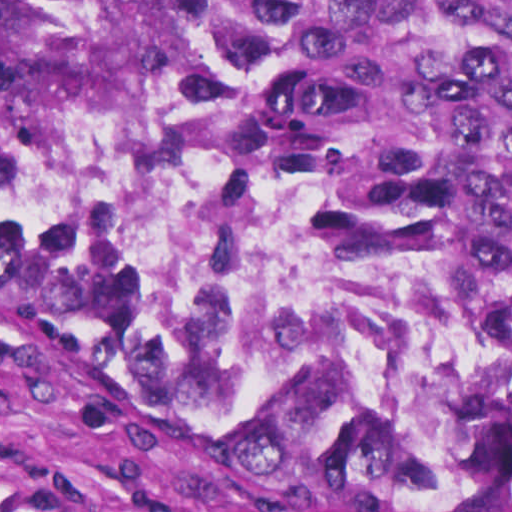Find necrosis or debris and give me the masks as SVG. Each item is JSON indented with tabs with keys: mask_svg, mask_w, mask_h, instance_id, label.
Instances as JSON below:
<instances>
[{
	"mask_svg": "<svg viewBox=\"0 0 512 512\" xmlns=\"http://www.w3.org/2000/svg\"><path fill=\"white\" fill-rule=\"evenodd\" d=\"M0 169L77 215L202 376L278 430L408 417L455 389L464 299L368 208L263 159H107L1 82Z\"/></svg>",
	"mask_w": 512,
	"mask_h": 512,
	"instance_id": "necrosis-or-debris-1",
	"label": "necrosis or debris"
}]
</instances>
